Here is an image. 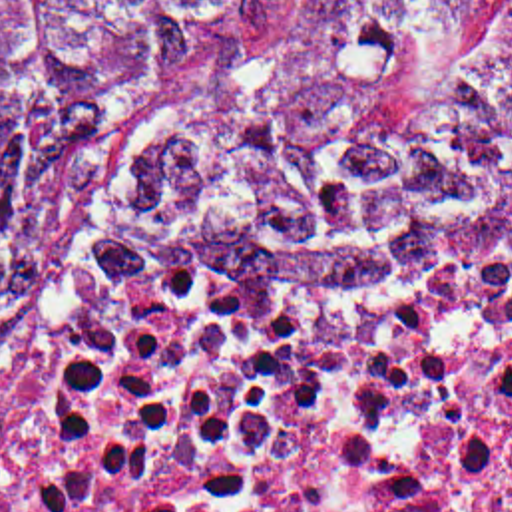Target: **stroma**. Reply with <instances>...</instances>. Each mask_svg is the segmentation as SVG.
<instances>
[{
	"mask_svg": "<svg viewBox=\"0 0 512 512\" xmlns=\"http://www.w3.org/2000/svg\"><path fill=\"white\" fill-rule=\"evenodd\" d=\"M313 2L314 0H289L269 22L243 38L225 54L195 68L167 95V99L149 119V123L141 129V133L135 137V141L107 175L101 221L105 215H125L133 187L147 163L151 161L157 145L193 123L213 105L229 99L243 77L269 52L277 50L289 40V36L299 26L303 10ZM510 273L496 275L480 283L500 281Z\"/></svg>",
	"mask_w": 512,
	"mask_h": 512,
	"instance_id": "1",
	"label": "stroma"
}]
</instances>
